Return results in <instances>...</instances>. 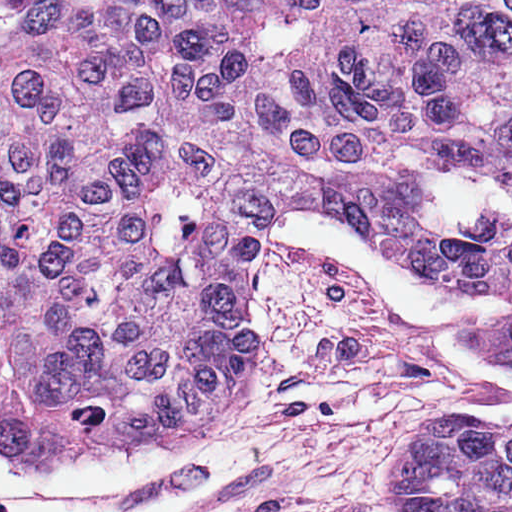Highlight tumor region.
<instances>
[{"mask_svg":"<svg viewBox=\"0 0 512 512\" xmlns=\"http://www.w3.org/2000/svg\"><path fill=\"white\" fill-rule=\"evenodd\" d=\"M318 206L504 296L512 368V0H0V450L191 443ZM399 492L512 512V418L427 433Z\"/></svg>","mask_w":512,"mask_h":512,"instance_id":"1","label":"tumor region"}]
</instances>
